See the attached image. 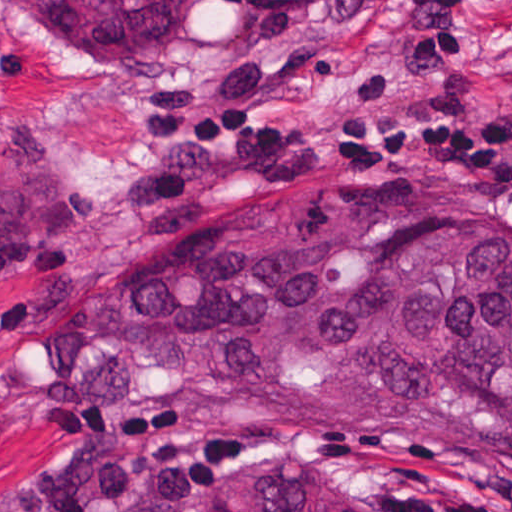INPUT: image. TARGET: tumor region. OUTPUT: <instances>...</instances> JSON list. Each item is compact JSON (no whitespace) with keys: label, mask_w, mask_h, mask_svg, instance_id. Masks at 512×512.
I'll return each mask as SVG.
<instances>
[{"label":"tumor region","mask_w":512,"mask_h":512,"mask_svg":"<svg viewBox=\"0 0 512 512\" xmlns=\"http://www.w3.org/2000/svg\"><path fill=\"white\" fill-rule=\"evenodd\" d=\"M197 0H0L77 54L150 51ZM306 16L343 0H214ZM64 237V199L0 187V288ZM24 376L53 408L125 416L190 384L226 411L358 452H464L512 465V199L424 187L264 197L91 281ZM203 512H367L305 474L233 478Z\"/></svg>","instance_id":"e687c5a6"}]
</instances>
